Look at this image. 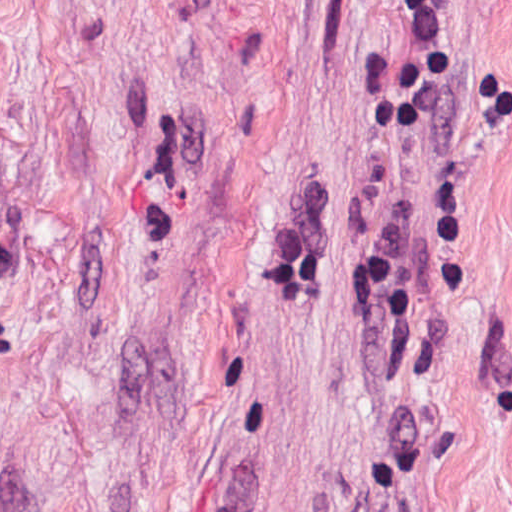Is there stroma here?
Masks as SVG:
<instances>
[{
  "instance_id": "stroma-1",
  "label": "stroma",
  "mask_w": 512,
  "mask_h": 512,
  "mask_svg": "<svg viewBox=\"0 0 512 512\" xmlns=\"http://www.w3.org/2000/svg\"><path fill=\"white\" fill-rule=\"evenodd\" d=\"M441 3L370 138L404 0H0V512H512V0Z\"/></svg>"
}]
</instances>
